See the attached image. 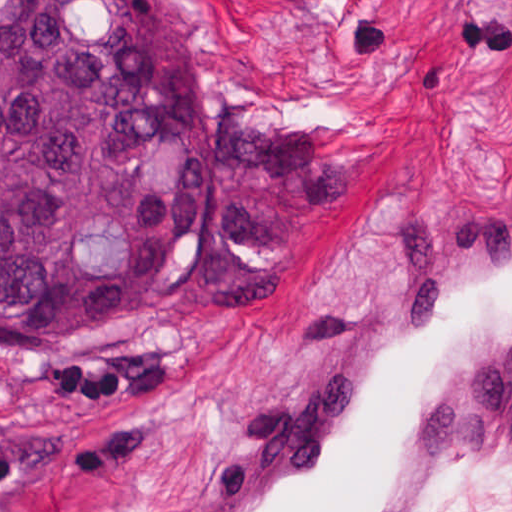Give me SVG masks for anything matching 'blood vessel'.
Instances as JSON below:
<instances>
[{"label":"blood vessel","mask_w":512,"mask_h":512,"mask_svg":"<svg viewBox=\"0 0 512 512\" xmlns=\"http://www.w3.org/2000/svg\"><path fill=\"white\" fill-rule=\"evenodd\" d=\"M512 430V185L437 208L174 512H428Z\"/></svg>","instance_id":"8fb6f2fc"}]
</instances>
